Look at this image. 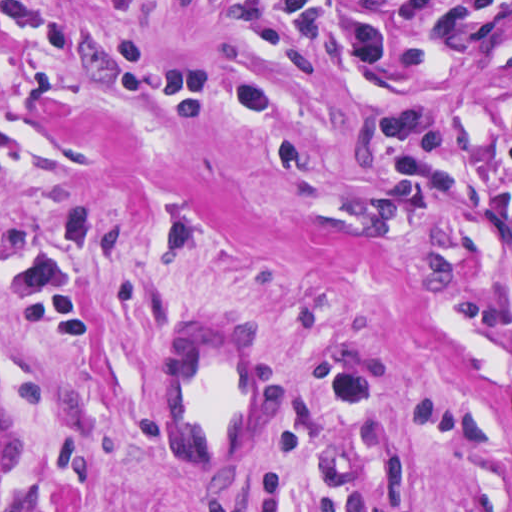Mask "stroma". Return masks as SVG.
I'll list each match as a JSON object with an SVG mask.
<instances>
[{
  "mask_svg": "<svg viewBox=\"0 0 512 512\" xmlns=\"http://www.w3.org/2000/svg\"><path fill=\"white\" fill-rule=\"evenodd\" d=\"M207 308L283 355L227 476ZM0 512H512V0H0Z\"/></svg>",
  "mask_w": 512,
  "mask_h": 512,
  "instance_id": "obj_1",
  "label": "stroma"
}]
</instances>
